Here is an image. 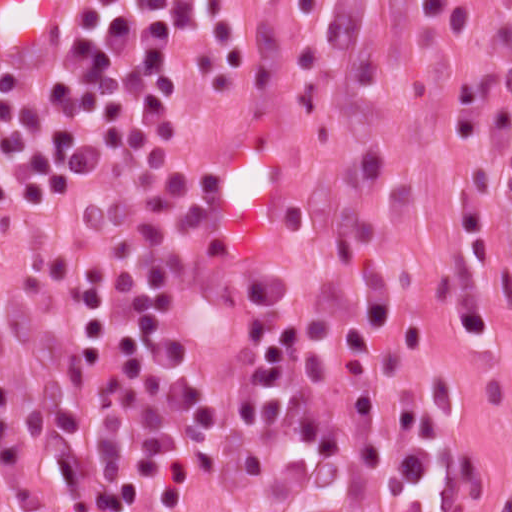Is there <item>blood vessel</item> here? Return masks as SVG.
<instances>
[{"label":"blood vessel","instance_id":"obj_1","mask_svg":"<svg viewBox=\"0 0 512 512\" xmlns=\"http://www.w3.org/2000/svg\"><path fill=\"white\" fill-rule=\"evenodd\" d=\"M78 0H0V79H24L65 43ZM292 208V176L265 120L212 148L199 176L196 236L207 255L264 241Z\"/></svg>","mask_w":512,"mask_h":512}]
</instances>
